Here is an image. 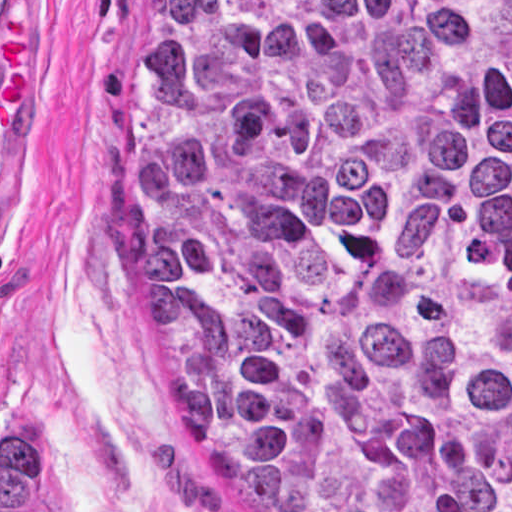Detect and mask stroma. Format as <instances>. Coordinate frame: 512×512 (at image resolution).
Listing matches in <instances>:
<instances>
[{
  "mask_svg": "<svg viewBox=\"0 0 512 512\" xmlns=\"http://www.w3.org/2000/svg\"><path fill=\"white\" fill-rule=\"evenodd\" d=\"M131 0H0L1 456L35 512H265L195 449L144 355L129 261Z\"/></svg>",
  "mask_w": 512,
  "mask_h": 512,
  "instance_id": "1",
  "label": "stroma"
}]
</instances>
